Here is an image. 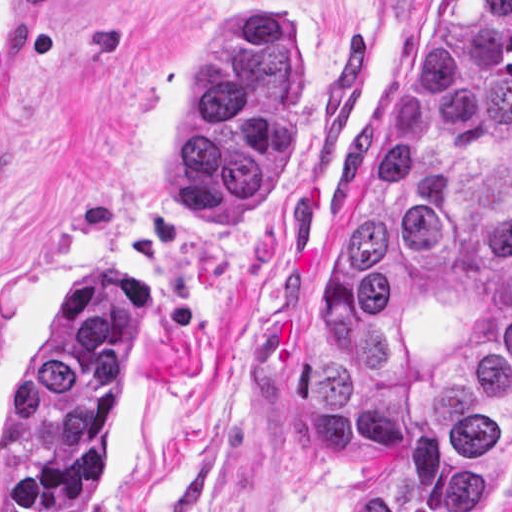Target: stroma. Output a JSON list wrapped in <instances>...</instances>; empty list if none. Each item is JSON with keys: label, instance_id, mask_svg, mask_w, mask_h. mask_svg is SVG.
Wrapping results in <instances>:
<instances>
[{"label": "stroma", "instance_id": "obj_1", "mask_svg": "<svg viewBox=\"0 0 512 512\" xmlns=\"http://www.w3.org/2000/svg\"><path fill=\"white\" fill-rule=\"evenodd\" d=\"M430 1L44 0L36 131L0 188V476L33 352L73 294L120 276L143 323L94 512H335L305 380L311 244ZM264 5L299 67L298 126L266 207L222 233L157 200L156 157L212 23Z\"/></svg>", "mask_w": 512, "mask_h": 512}]
</instances>
